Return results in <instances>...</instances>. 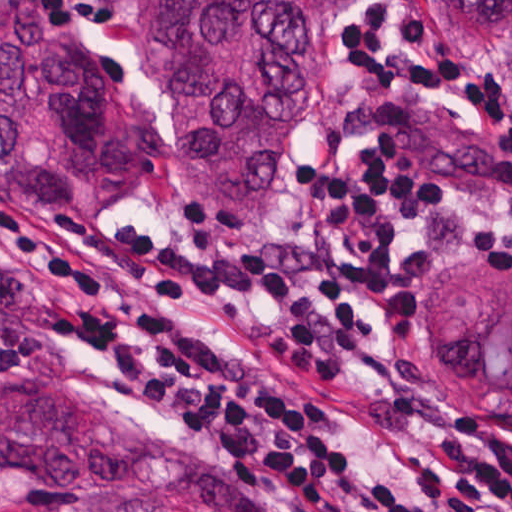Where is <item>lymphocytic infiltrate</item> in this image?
<instances>
[{
    "label": "lymphocytic infiltrate",
    "instance_id": "lymphocytic-infiltrate-1",
    "mask_svg": "<svg viewBox=\"0 0 512 512\" xmlns=\"http://www.w3.org/2000/svg\"><path fill=\"white\" fill-rule=\"evenodd\" d=\"M68 32L107 27L96 0H38ZM397 25L366 0L341 34L373 88L328 128L333 150L364 130L347 168L310 164L308 197L355 261L314 241L223 246L108 225L69 235L0 203V381L38 360L44 322L80 341L111 375L184 432L257 478L337 512H512V439L484 419L434 438L416 459L419 494L383 476L276 366L183 319L177 297L279 305L264 345L317 381L344 377L378 336L375 317H409L426 269L417 218H442L512 265V94L488 68L439 52L414 8ZM359 301L369 313L355 308Z\"/></svg>",
    "mask_w": 512,
    "mask_h": 512
}]
</instances>
